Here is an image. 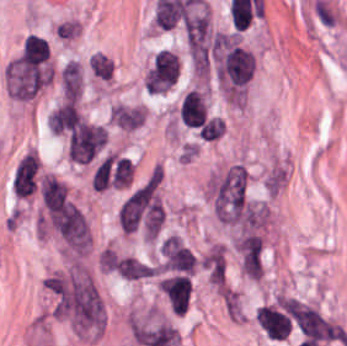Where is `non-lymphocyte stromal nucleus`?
<instances>
[{
  "instance_id": "dd21d789",
  "label": "non-lymphocyte stromal nucleus",
  "mask_w": 347,
  "mask_h": 346,
  "mask_svg": "<svg viewBox=\"0 0 347 346\" xmlns=\"http://www.w3.org/2000/svg\"><path fill=\"white\" fill-rule=\"evenodd\" d=\"M106 131L103 126L82 121L73 130L68 155L79 163H86L98 155L105 145Z\"/></svg>"
},
{
  "instance_id": "a72fc3eb",
  "label": "non-lymphocyte stromal nucleus",
  "mask_w": 347,
  "mask_h": 346,
  "mask_svg": "<svg viewBox=\"0 0 347 346\" xmlns=\"http://www.w3.org/2000/svg\"><path fill=\"white\" fill-rule=\"evenodd\" d=\"M158 288L177 313L184 315L189 308L193 282L185 273H166L158 280Z\"/></svg>"
},
{
  "instance_id": "3746e769",
  "label": "non-lymphocyte stromal nucleus",
  "mask_w": 347,
  "mask_h": 346,
  "mask_svg": "<svg viewBox=\"0 0 347 346\" xmlns=\"http://www.w3.org/2000/svg\"><path fill=\"white\" fill-rule=\"evenodd\" d=\"M161 269L184 273L194 272L195 256L175 236H168L160 246Z\"/></svg>"
},
{
  "instance_id": "fc2b8d12",
  "label": "non-lymphocyte stromal nucleus",
  "mask_w": 347,
  "mask_h": 346,
  "mask_svg": "<svg viewBox=\"0 0 347 346\" xmlns=\"http://www.w3.org/2000/svg\"><path fill=\"white\" fill-rule=\"evenodd\" d=\"M179 77V58L169 49H162L153 59L150 70L151 88H169Z\"/></svg>"
},
{
  "instance_id": "81446118",
  "label": "non-lymphocyte stromal nucleus",
  "mask_w": 347,
  "mask_h": 346,
  "mask_svg": "<svg viewBox=\"0 0 347 346\" xmlns=\"http://www.w3.org/2000/svg\"><path fill=\"white\" fill-rule=\"evenodd\" d=\"M201 264L213 284H224L226 278V256L224 248L213 244L201 257Z\"/></svg>"
},
{
  "instance_id": "7c5642bf",
  "label": "non-lymphocyte stromal nucleus",
  "mask_w": 347,
  "mask_h": 346,
  "mask_svg": "<svg viewBox=\"0 0 347 346\" xmlns=\"http://www.w3.org/2000/svg\"><path fill=\"white\" fill-rule=\"evenodd\" d=\"M145 117V107L124 103L113 105L109 113V118L119 127L133 130L145 121Z\"/></svg>"
},
{
  "instance_id": "9d01c50a",
  "label": "non-lymphocyte stromal nucleus",
  "mask_w": 347,
  "mask_h": 346,
  "mask_svg": "<svg viewBox=\"0 0 347 346\" xmlns=\"http://www.w3.org/2000/svg\"><path fill=\"white\" fill-rule=\"evenodd\" d=\"M44 204L50 210H60L66 205L67 186L52 176H45L41 183Z\"/></svg>"
}]
</instances>
